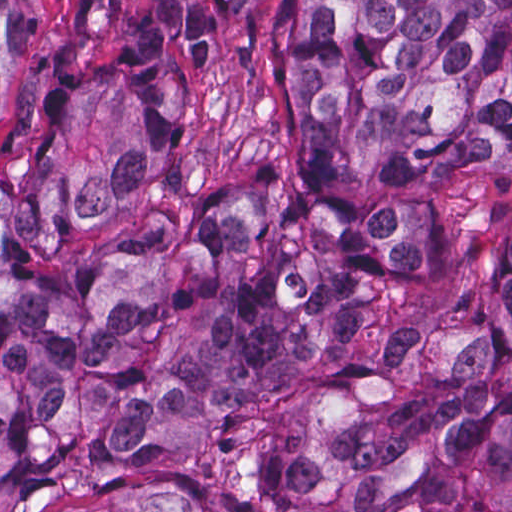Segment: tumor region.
<instances>
[{
	"label": "tumor region",
	"mask_w": 512,
	"mask_h": 512,
	"mask_svg": "<svg viewBox=\"0 0 512 512\" xmlns=\"http://www.w3.org/2000/svg\"><path fill=\"white\" fill-rule=\"evenodd\" d=\"M0 512H512V0H143L0 169Z\"/></svg>",
	"instance_id": "obj_1"
}]
</instances>
